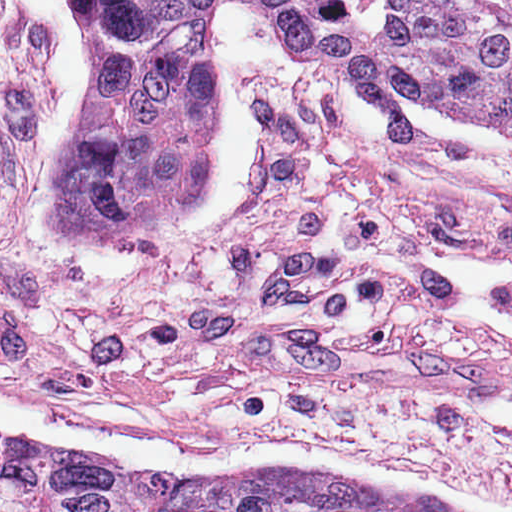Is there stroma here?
I'll return each mask as SVG.
<instances>
[{"label": "stroma", "mask_w": 512, "mask_h": 512, "mask_svg": "<svg viewBox=\"0 0 512 512\" xmlns=\"http://www.w3.org/2000/svg\"><path fill=\"white\" fill-rule=\"evenodd\" d=\"M211 186L152 244L72 240L177 473L285 465L512 512V150L382 136L354 63L219 0ZM83 0H0L48 186L90 97Z\"/></svg>", "instance_id": "stroma-1"}]
</instances>
